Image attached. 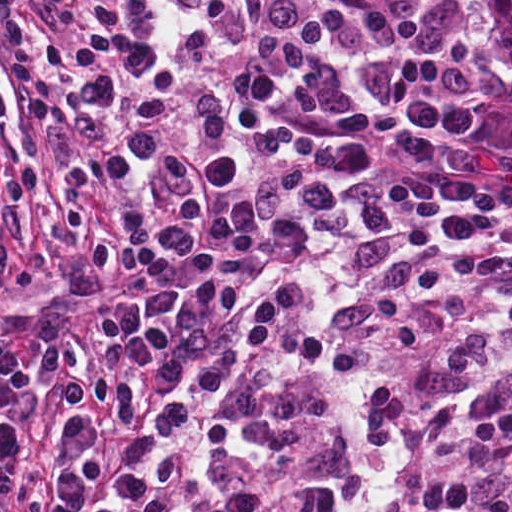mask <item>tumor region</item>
Returning <instances> with one entry per match:
<instances>
[{"label":"tumor region","mask_w":512,"mask_h":512,"mask_svg":"<svg viewBox=\"0 0 512 512\" xmlns=\"http://www.w3.org/2000/svg\"><path fill=\"white\" fill-rule=\"evenodd\" d=\"M495 27L512 57V0H487Z\"/></svg>","instance_id":"obj_1"}]
</instances>
